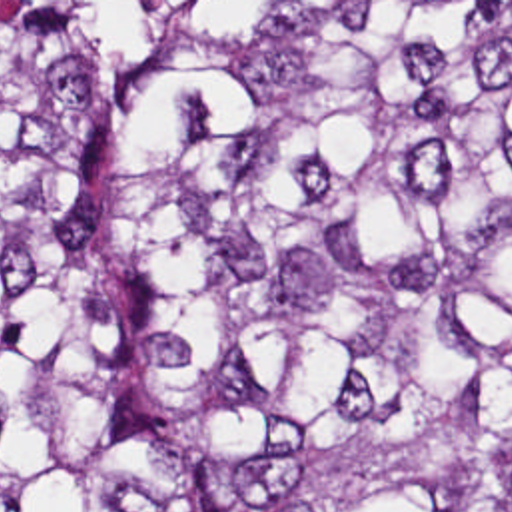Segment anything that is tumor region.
Returning <instances> with one entry per match:
<instances>
[{"label":"tumor region","mask_w":512,"mask_h":512,"mask_svg":"<svg viewBox=\"0 0 512 512\" xmlns=\"http://www.w3.org/2000/svg\"><path fill=\"white\" fill-rule=\"evenodd\" d=\"M0 512H512V2H0Z\"/></svg>","instance_id":"obj_1"}]
</instances>
